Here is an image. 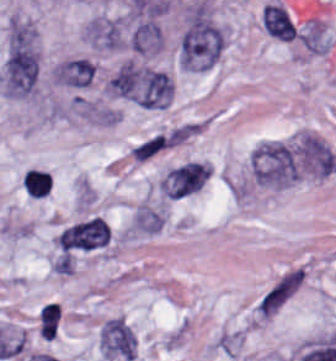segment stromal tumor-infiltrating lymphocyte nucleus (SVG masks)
Returning <instances> with one entry per match:
<instances>
[{"label": "stromal tumor-infiltrating lymphocyte nucleus", "mask_w": 336, "mask_h": 361, "mask_svg": "<svg viewBox=\"0 0 336 361\" xmlns=\"http://www.w3.org/2000/svg\"><path fill=\"white\" fill-rule=\"evenodd\" d=\"M24 190L35 198L45 197L50 188V173L36 169L29 168L23 175Z\"/></svg>", "instance_id": "1"}, {"label": "stromal tumor-infiltrating lymphocyte nucleus", "mask_w": 336, "mask_h": 361, "mask_svg": "<svg viewBox=\"0 0 336 361\" xmlns=\"http://www.w3.org/2000/svg\"><path fill=\"white\" fill-rule=\"evenodd\" d=\"M61 307L55 303H47L39 312L41 335L44 340H52L58 330Z\"/></svg>", "instance_id": "2"}]
</instances>
